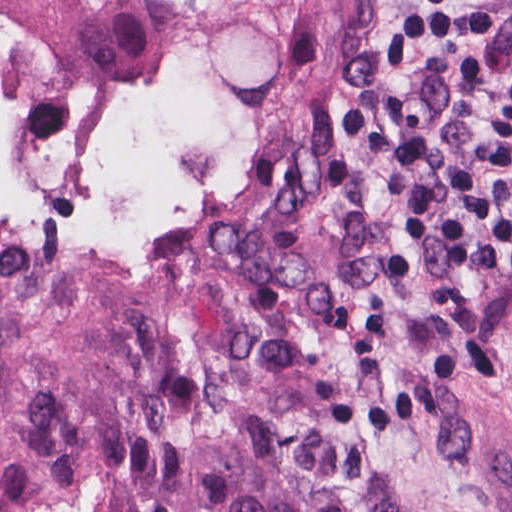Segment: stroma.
I'll return each instance as SVG.
<instances>
[{
  "label": "stroma",
  "mask_w": 512,
  "mask_h": 512,
  "mask_svg": "<svg viewBox=\"0 0 512 512\" xmlns=\"http://www.w3.org/2000/svg\"><path fill=\"white\" fill-rule=\"evenodd\" d=\"M398 0H203L141 93L109 102L0 74L25 101L132 117L197 73L203 148L248 136L366 153L337 99L386 32ZM498 10L487 73L512 88V0ZM197 228L274 234L279 263L430 434L512 509V282L484 257L447 260L370 202L366 156L304 162ZM186 229L166 232L135 240ZM105 241L0 248V259H72Z\"/></svg>",
  "instance_id": "35a3bbf8"
}]
</instances>
